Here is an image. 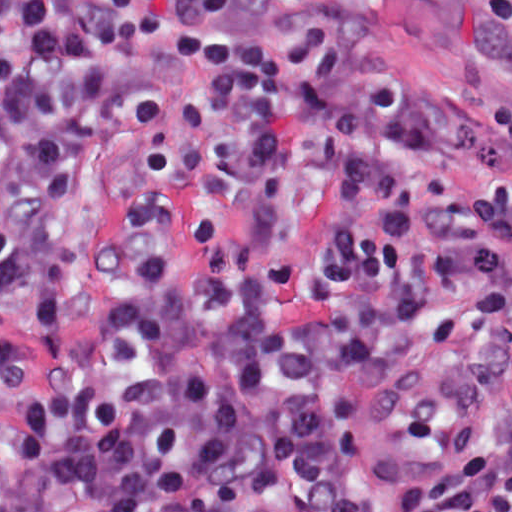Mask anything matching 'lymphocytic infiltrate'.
I'll return each mask as SVG.
<instances>
[{
	"mask_svg": "<svg viewBox=\"0 0 512 512\" xmlns=\"http://www.w3.org/2000/svg\"><path fill=\"white\" fill-rule=\"evenodd\" d=\"M237 1L1 0V512H512V263L416 239L441 100L337 3L189 36L90 242L98 331L57 345L73 195L151 112L146 50ZM420 1L471 51L512 28V0ZM474 144L512 236V105Z\"/></svg>",
	"mask_w": 512,
	"mask_h": 512,
	"instance_id": "1",
	"label": "lymphocytic infiltrate"
}]
</instances>
